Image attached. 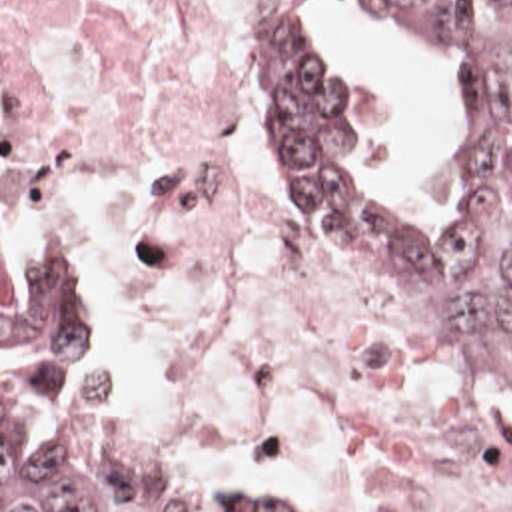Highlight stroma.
Masks as SVG:
<instances>
[{
    "instance_id": "stroma-1",
    "label": "stroma",
    "mask_w": 512,
    "mask_h": 512,
    "mask_svg": "<svg viewBox=\"0 0 512 512\" xmlns=\"http://www.w3.org/2000/svg\"><path fill=\"white\" fill-rule=\"evenodd\" d=\"M300 9H308L313 11L315 17H317V9H315V1L313 0H300L298 3ZM365 13L369 17H373L377 23H381L385 27V31L389 33V37L395 41V45L399 47V51L411 59L421 71H425L433 81H437L443 89V95H445V101H447V109H449V207L447 211L453 209L455 205V197H457V191H459V117H457V109H455V101H453V95H451V89H449V83H447V77L441 69H437L429 57L423 53V49L405 33L385 25L381 19H377L373 13H369L365 9ZM276 153V151H274ZM278 157V163H280V169L284 173V179L288 183V187L292 189L294 197L298 199V203L302 205L308 221H310L311 233L315 237V243L317 247L321 249V253L327 257V261L333 265L335 271L343 273V275H349V277H355L359 281H365L369 283L373 289H377L385 299H389L403 315H407L417 327L433 333V335H439L447 341L453 343V347L457 349L455 341L437 325L433 323L425 313H421L415 305H411L407 299H403L399 293H395L391 287H387L385 283H381L379 279H375L373 275H369L367 271H363L361 267L353 265L351 261H347L343 257V253L337 249V245L315 225L313 217L308 211V207L304 205V201L300 199L296 187H294V179H292V173L290 169L286 167V163L280 159V155L276 153ZM389 225L393 227H399V229H405V231H411V233H417L413 231L411 227V221H387ZM18 243H46L48 247H52L56 253H60L68 265L74 269V273L78 275L84 291H86V297L92 305V311H94V287L90 283V277H88V271L84 267V261L80 257V253L76 251L74 243L70 241V237L66 235L64 227L8 201L2 197V0H0V357H2V253L12 249L14 245ZM459 353V349H457ZM461 357V353H459ZM463 359V357H461ZM463 363L467 365L469 373L475 377V381L483 387V391L491 397V401L497 405V409L501 411L503 419L507 421V425L511 427L512 431V399L497 385L493 383L489 377H485L479 369H475L471 363H467L463 359ZM100 421L106 429V421H104V413H102V403H100ZM108 433V431H106ZM110 441L124 453L128 455L130 459H134L136 463L160 473V475H166L194 491H200L204 495H210V497H282L268 481H262V479H252V477H242V475H234V473H224V471H214V469H206V467H200V465H194V463H186V461H180V459H174V457H166V455H156V453H144V451H136L116 439L110 437ZM0 512H2V387H0Z\"/></svg>"
}]
</instances>
